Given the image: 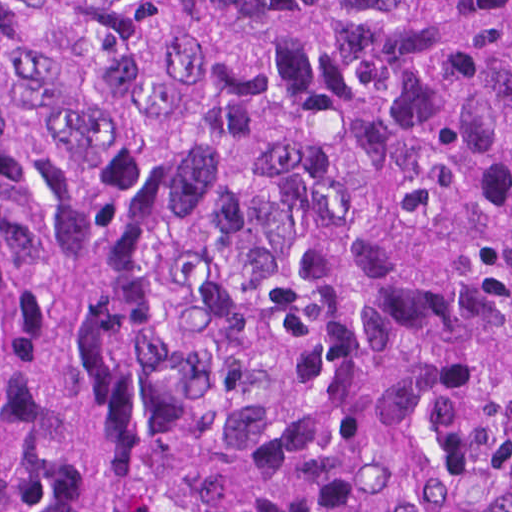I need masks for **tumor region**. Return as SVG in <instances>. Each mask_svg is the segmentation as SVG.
<instances>
[{"label":"tumor region","instance_id":"e687c5a6","mask_svg":"<svg viewBox=\"0 0 512 512\" xmlns=\"http://www.w3.org/2000/svg\"><path fill=\"white\" fill-rule=\"evenodd\" d=\"M0 512H512V0H0Z\"/></svg>","mask_w":512,"mask_h":512}]
</instances>
